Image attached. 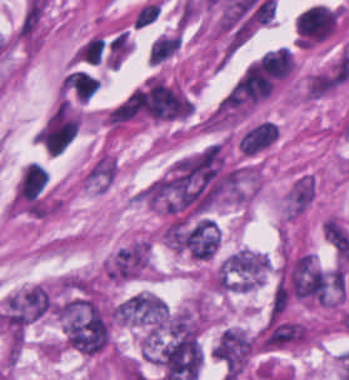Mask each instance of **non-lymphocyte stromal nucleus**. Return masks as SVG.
<instances>
[{
  "mask_svg": "<svg viewBox=\"0 0 349 380\" xmlns=\"http://www.w3.org/2000/svg\"><path fill=\"white\" fill-rule=\"evenodd\" d=\"M316 180L307 172L295 176L285 195L282 210L283 216L296 217L303 213L315 195Z\"/></svg>",
  "mask_w": 349,
  "mask_h": 380,
  "instance_id": "obj_1",
  "label": "non-lymphocyte stromal nucleus"
},
{
  "mask_svg": "<svg viewBox=\"0 0 349 380\" xmlns=\"http://www.w3.org/2000/svg\"><path fill=\"white\" fill-rule=\"evenodd\" d=\"M277 134V125L269 121H262L242 136L238 142L240 150L247 154L257 153L272 143Z\"/></svg>",
  "mask_w": 349,
  "mask_h": 380,
  "instance_id": "obj_2",
  "label": "non-lymphocyte stromal nucleus"
}]
</instances>
